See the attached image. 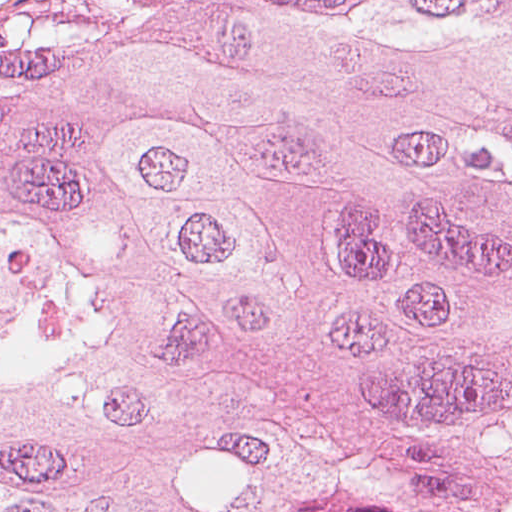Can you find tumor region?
<instances>
[{"instance_id":"tumor-region-1","label":"tumor region","mask_w":512,"mask_h":512,"mask_svg":"<svg viewBox=\"0 0 512 512\" xmlns=\"http://www.w3.org/2000/svg\"><path fill=\"white\" fill-rule=\"evenodd\" d=\"M0 512H512V0L0 20Z\"/></svg>"}]
</instances>
